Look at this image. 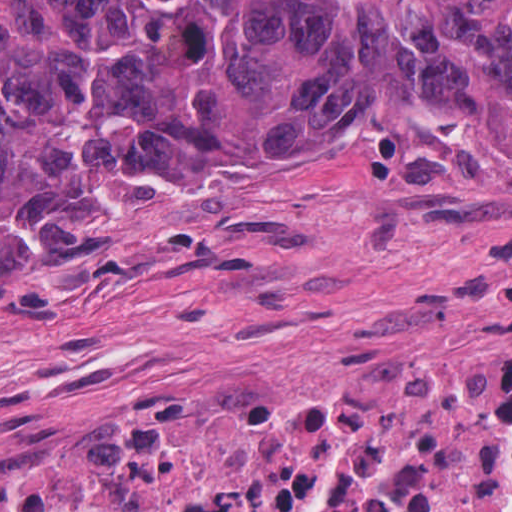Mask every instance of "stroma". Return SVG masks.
Wrapping results in <instances>:
<instances>
[{
    "mask_svg": "<svg viewBox=\"0 0 512 512\" xmlns=\"http://www.w3.org/2000/svg\"><path fill=\"white\" fill-rule=\"evenodd\" d=\"M97 203L131 215L119 250L0 300V480L74 473L231 375L512 358V144L130 159Z\"/></svg>",
    "mask_w": 512,
    "mask_h": 512,
    "instance_id": "35a3bbf8",
    "label": "stroma"
}]
</instances>
